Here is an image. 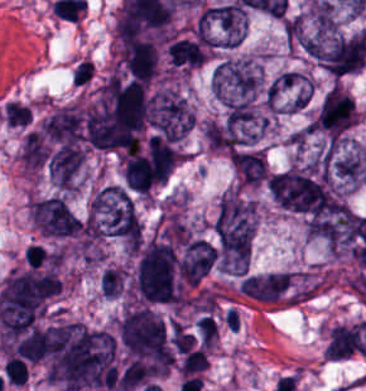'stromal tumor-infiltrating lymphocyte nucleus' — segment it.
<instances>
[{"mask_svg": "<svg viewBox=\"0 0 366 391\" xmlns=\"http://www.w3.org/2000/svg\"><path fill=\"white\" fill-rule=\"evenodd\" d=\"M201 343L208 349H212L217 340V327L212 316H205L196 325Z\"/></svg>", "mask_w": 366, "mask_h": 391, "instance_id": "obj_1", "label": "stromal tumor-infiltrating lymphocyte nucleus"}, {"mask_svg": "<svg viewBox=\"0 0 366 391\" xmlns=\"http://www.w3.org/2000/svg\"><path fill=\"white\" fill-rule=\"evenodd\" d=\"M95 72V66L90 59H82L71 73L73 86L83 87L88 84Z\"/></svg>", "mask_w": 366, "mask_h": 391, "instance_id": "obj_2", "label": "stromal tumor-infiltrating lymphocyte nucleus"}]
</instances>
